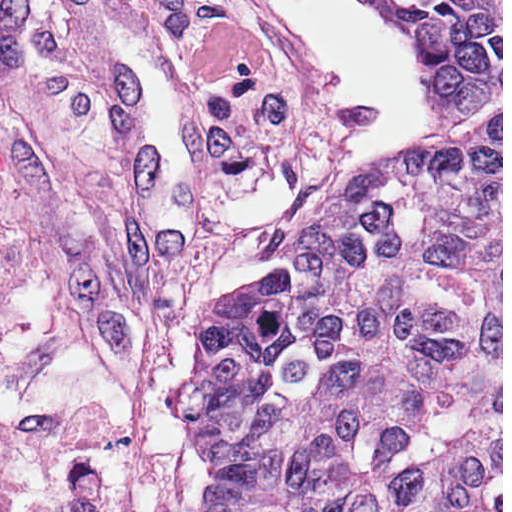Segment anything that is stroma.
Wrapping results in <instances>:
<instances>
[{"mask_svg":"<svg viewBox=\"0 0 512 512\" xmlns=\"http://www.w3.org/2000/svg\"><path fill=\"white\" fill-rule=\"evenodd\" d=\"M5 512H146L0 183Z\"/></svg>","mask_w":512,"mask_h":512,"instance_id":"obj_1","label":"stroma"}]
</instances>
